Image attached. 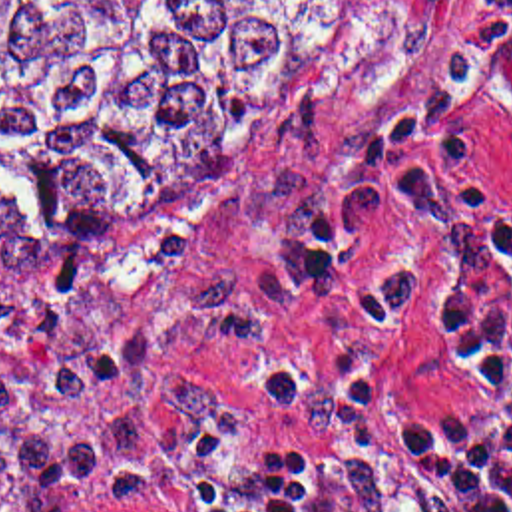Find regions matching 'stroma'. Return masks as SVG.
I'll return each mask as SVG.
<instances>
[{"instance_id":"1","label":"stroma","mask_w":512,"mask_h":512,"mask_svg":"<svg viewBox=\"0 0 512 512\" xmlns=\"http://www.w3.org/2000/svg\"><path fill=\"white\" fill-rule=\"evenodd\" d=\"M473 4L368 0L358 30L312 93L244 145L188 209L117 231L83 253L0 261L5 306L39 302L61 259H83L107 282L101 286L131 302H168L206 274L240 271L278 312V334L260 346L190 338L158 344L176 368L230 392L232 408L172 430L129 468L3 492L0 512L17 511L49 488L147 470L196 434H222L304 464L338 512H445L391 438L407 422L441 432L475 418L439 320L425 306L399 326L376 330L352 310L417 263L425 245L417 211L407 205L381 219L356 251L344 290L334 294L308 284L302 231L354 141L461 39ZM471 107L485 161L512 199V75L479 81ZM61 512L147 511L69 504Z\"/></svg>"}]
</instances>
